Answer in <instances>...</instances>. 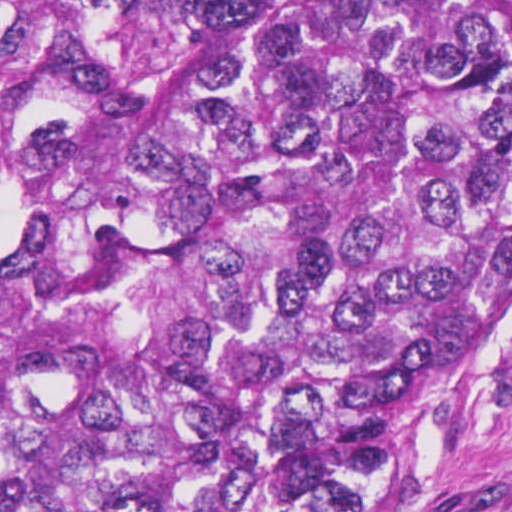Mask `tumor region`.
I'll return each mask as SVG.
<instances>
[{
	"instance_id": "1",
	"label": "tumor region",
	"mask_w": 512,
	"mask_h": 512,
	"mask_svg": "<svg viewBox=\"0 0 512 512\" xmlns=\"http://www.w3.org/2000/svg\"><path fill=\"white\" fill-rule=\"evenodd\" d=\"M512 307V0H0V512H354Z\"/></svg>"
}]
</instances>
